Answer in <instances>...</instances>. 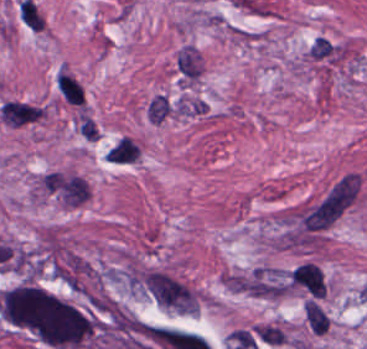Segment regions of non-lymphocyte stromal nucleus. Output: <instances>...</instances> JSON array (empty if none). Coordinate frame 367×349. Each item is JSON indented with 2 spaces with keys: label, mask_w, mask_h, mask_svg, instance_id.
I'll list each match as a JSON object with an SVG mask.
<instances>
[{
  "label": "non-lymphocyte stromal nucleus",
  "mask_w": 367,
  "mask_h": 349,
  "mask_svg": "<svg viewBox=\"0 0 367 349\" xmlns=\"http://www.w3.org/2000/svg\"><path fill=\"white\" fill-rule=\"evenodd\" d=\"M43 188L65 205H78L85 200L87 181L79 176L50 172L43 175Z\"/></svg>",
  "instance_id": "a72fc3eb"
},
{
  "label": "non-lymphocyte stromal nucleus",
  "mask_w": 367,
  "mask_h": 349,
  "mask_svg": "<svg viewBox=\"0 0 367 349\" xmlns=\"http://www.w3.org/2000/svg\"><path fill=\"white\" fill-rule=\"evenodd\" d=\"M222 283L231 291L265 299L281 298L289 289L281 268L265 264L226 272Z\"/></svg>",
  "instance_id": "dd21d789"
},
{
  "label": "non-lymphocyte stromal nucleus",
  "mask_w": 367,
  "mask_h": 349,
  "mask_svg": "<svg viewBox=\"0 0 367 349\" xmlns=\"http://www.w3.org/2000/svg\"><path fill=\"white\" fill-rule=\"evenodd\" d=\"M138 154L139 147L123 135L107 150L105 156L112 161H134Z\"/></svg>",
  "instance_id": "3746e769"
}]
</instances>
